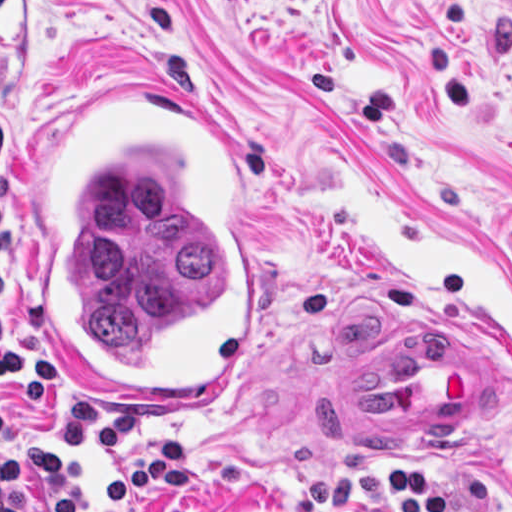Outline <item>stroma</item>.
Returning a JSON list of instances; mask_svg holds the SVG:
<instances>
[{
  "instance_id": "obj_1",
  "label": "stroma",
  "mask_w": 512,
  "mask_h": 512,
  "mask_svg": "<svg viewBox=\"0 0 512 512\" xmlns=\"http://www.w3.org/2000/svg\"><path fill=\"white\" fill-rule=\"evenodd\" d=\"M152 79L211 108L259 169L263 334L209 407L93 403L148 410L135 455L161 434L195 441L188 486L123 512H293L311 476L344 473L322 418L329 383L434 335L488 353L481 425L357 455L416 467L454 502L473 465L512 489V0H0V223L17 234L6 330L25 344L40 145L63 109ZM62 382L32 411L0 384L12 430L55 449L80 399ZM343 512L393 510L371 496Z\"/></svg>"
}]
</instances>
